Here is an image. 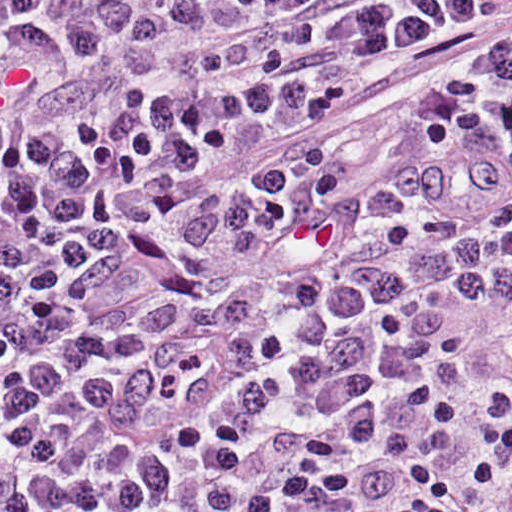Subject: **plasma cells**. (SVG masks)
Masks as SVG:
<instances>
[{"mask_svg": "<svg viewBox=\"0 0 512 512\" xmlns=\"http://www.w3.org/2000/svg\"><path fill=\"white\" fill-rule=\"evenodd\" d=\"M511 469L512 0H0V512Z\"/></svg>", "mask_w": 512, "mask_h": 512, "instance_id": "9512152a", "label": "plasma cells"}]
</instances>
